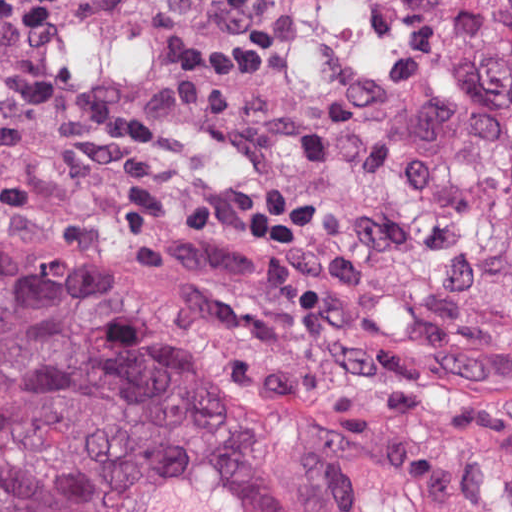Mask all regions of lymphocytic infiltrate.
<instances>
[{
    "label": "lymphocytic infiltrate",
    "instance_id": "lymphocytic-infiltrate-1",
    "mask_svg": "<svg viewBox=\"0 0 512 512\" xmlns=\"http://www.w3.org/2000/svg\"><path fill=\"white\" fill-rule=\"evenodd\" d=\"M55 1L0 5V141H29L88 157L127 154L137 137L127 108L45 78L25 59L37 21Z\"/></svg>",
    "mask_w": 512,
    "mask_h": 512
}]
</instances>
